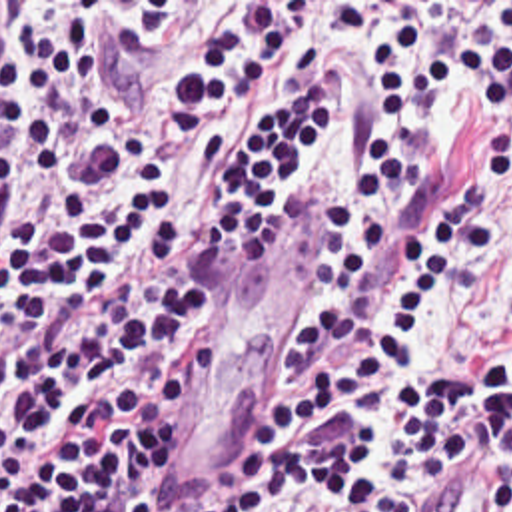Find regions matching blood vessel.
Returning a JSON list of instances; mask_svg holds the SVG:
<instances>
[{"label":"blood vessel","instance_id":"8fb6f2fc","mask_svg":"<svg viewBox=\"0 0 512 512\" xmlns=\"http://www.w3.org/2000/svg\"><path fill=\"white\" fill-rule=\"evenodd\" d=\"M14 46V2H0V102ZM509 455L505 447L483 443L465 451L451 467L435 512H505Z\"/></svg>","mask_w":512,"mask_h":512}]
</instances>
